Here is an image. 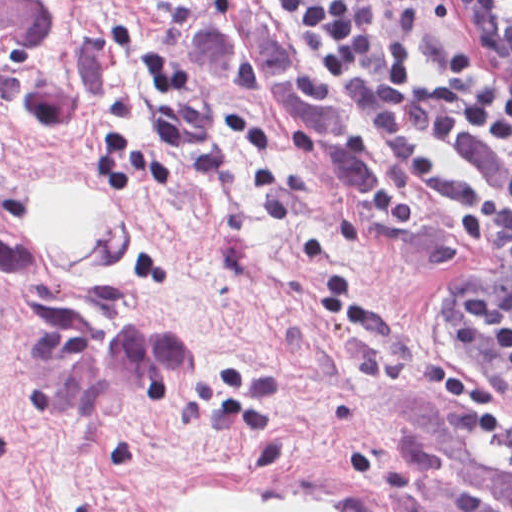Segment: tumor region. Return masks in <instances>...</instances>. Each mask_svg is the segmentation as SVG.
I'll use <instances>...</instances> for the list:
<instances>
[{
	"label": "tumor region",
	"instance_id": "obj_1",
	"mask_svg": "<svg viewBox=\"0 0 512 512\" xmlns=\"http://www.w3.org/2000/svg\"><path fill=\"white\" fill-rule=\"evenodd\" d=\"M184 54L198 87L275 102L338 161L357 196L372 195L380 156L320 75L278 40L254 0H198L184 23ZM0 88L33 120L80 107L81 79L54 0H0ZM486 421L503 424L394 393L385 440L414 512H512V446Z\"/></svg>",
	"mask_w": 512,
	"mask_h": 512
}]
</instances>
